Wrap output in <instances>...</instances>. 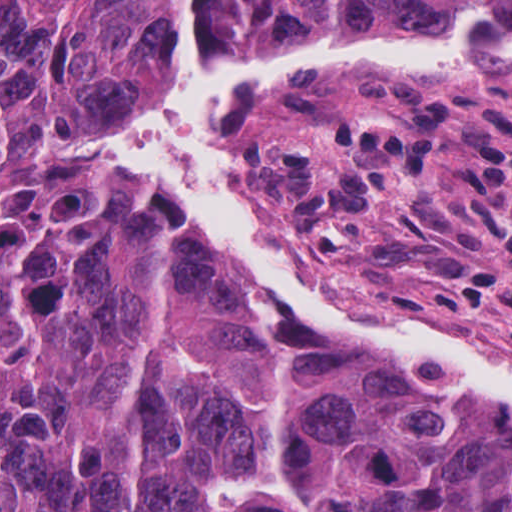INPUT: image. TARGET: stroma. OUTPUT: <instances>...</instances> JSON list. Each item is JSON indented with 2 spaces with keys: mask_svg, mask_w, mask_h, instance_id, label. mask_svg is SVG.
<instances>
[{
  "mask_svg": "<svg viewBox=\"0 0 512 512\" xmlns=\"http://www.w3.org/2000/svg\"><path fill=\"white\" fill-rule=\"evenodd\" d=\"M109 117L50 150L66 173L142 224L247 340L305 348L176 199L96 154ZM213 129L212 176L311 285L360 315L444 330L512 370V90L435 75L275 83L233 101Z\"/></svg>",
  "mask_w": 512,
  "mask_h": 512,
  "instance_id": "35a3bbf8",
  "label": "stroma"
}]
</instances>
